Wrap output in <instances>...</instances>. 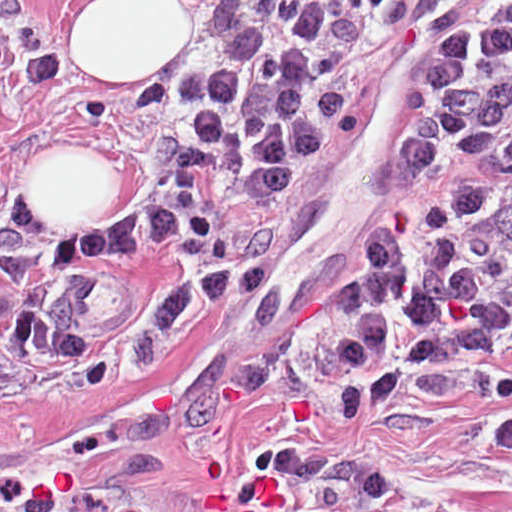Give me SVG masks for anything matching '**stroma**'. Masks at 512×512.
<instances>
[{
	"mask_svg": "<svg viewBox=\"0 0 512 512\" xmlns=\"http://www.w3.org/2000/svg\"><path fill=\"white\" fill-rule=\"evenodd\" d=\"M106 1H183L187 34L100 75L78 14ZM265 1H338L368 128L417 87L414 1L512 0H0V284L13 222L45 255L145 233L194 100ZM375 134L219 289L51 374H0V512H512V369L397 383L317 347L319 278L389 164ZM56 155L102 157L103 192L47 229L19 209Z\"/></svg>",
	"mask_w": 512,
	"mask_h": 512,
	"instance_id": "obj_1",
	"label": "stroma"
}]
</instances>
